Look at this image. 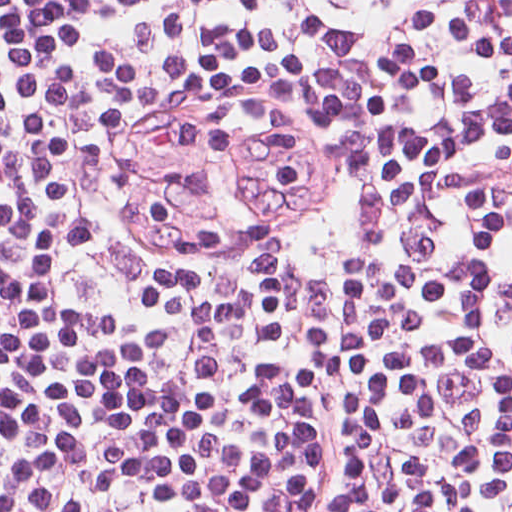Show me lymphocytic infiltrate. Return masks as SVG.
Instances as JSON below:
<instances>
[{"mask_svg": "<svg viewBox=\"0 0 512 512\" xmlns=\"http://www.w3.org/2000/svg\"><path fill=\"white\" fill-rule=\"evenodd\" d=\"M0 512H512V0H0Z\"/></svg>", "mask_w": 512, "mask_h": 512, "instance_id": "1", "label": "lymphocytic infiltrate"}]
</instances>
